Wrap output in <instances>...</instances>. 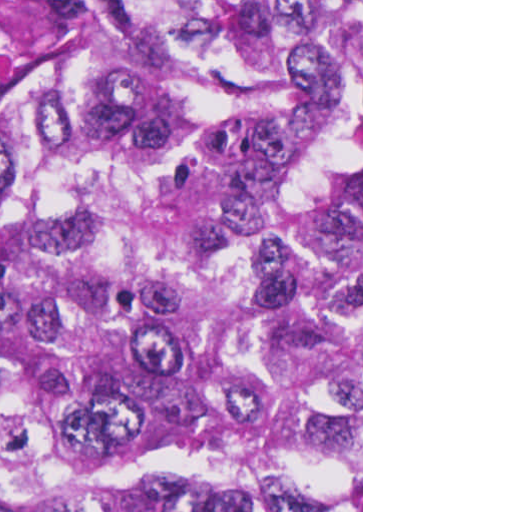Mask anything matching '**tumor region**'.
<instances>
[{
	"instance_id": "e687c5a6",
	"label": "tumor region",
	"mask_w": 512,
	"mask_h": 512,
	"mask_svg": "<svg viewBox=\"0 0 512 512\" xmlns=\"http://www.w3.org/2000/svg\"><path fill=\"white\" fill-rule=\"evenodd\" d=\"M0 93V512L361 485V0H77Z\"/></svg>"
}]
</instances>
